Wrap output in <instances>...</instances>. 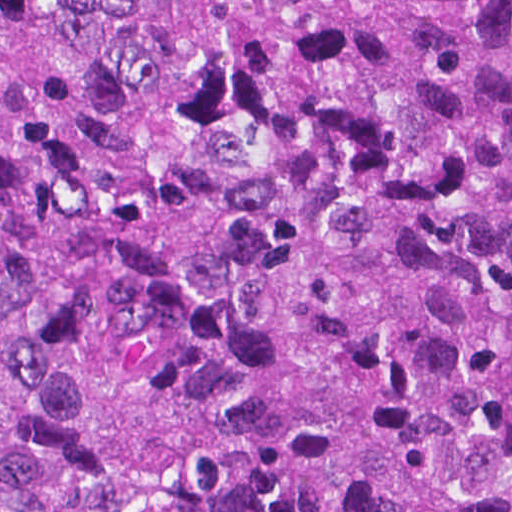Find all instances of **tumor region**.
Segmentation results:
<instances>
[{
    "mask_svg": "<svg viewBox=\"0 0 512 512\" xmlns=\"http://www.w3.org/2000/svg\"><path fill=\"white\" fill-rule=\"evenodd\" d=\"M0 512H512V0H0Z\"/></svg>",
    "mask_w": 512,
    "mask_h": 512,
    "instance_id": "obj_1",
    "label": "tumor region"
}]
</instances>
